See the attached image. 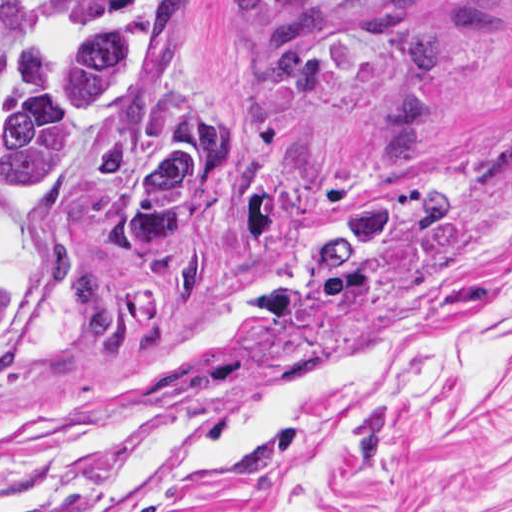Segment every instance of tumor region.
<instances>
[{
	"label": "tumor region",
	"instance_id": "obj_1",
	"mask_svg": "<svg viewBox=\"0 0 512 512\" xmlns=\"http://www.w3.org/2000/svg\"><path fill=\"white\" fill-rule=\"evenodd\" d=\"M148 1L84 0L99 18L36 45L0 81V357L24 326L5 220L76 239L134 287L201 263L286 122L303 71L362 0H243L220 106L156 123L108 156H81L150 90L154 58L139 35L101 19ZM188 14L189 0H152L157 84L176 76Z\"/></svg>",
	"mask_w": 512,
	"mask_h": 512
}]
</instances>
